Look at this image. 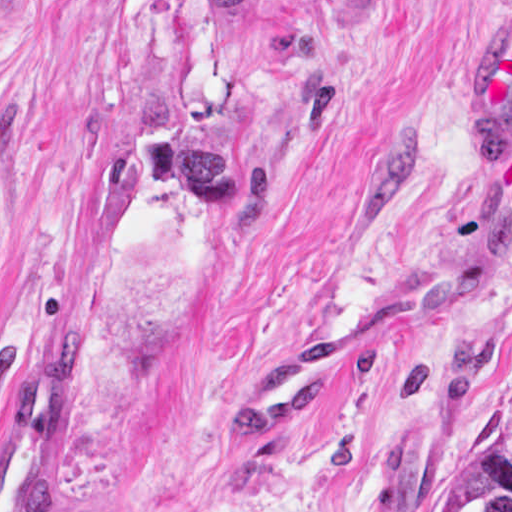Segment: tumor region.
<instances>
[{
	"label": "tumor region",
	"instance_id": "e687c5a6",
	"mask_svg": "<svg viewBox=\"0 0 512 512\" xmlns=\"http://www.w3.org/2000/svg\"><path fill=\"white\" fill-rule=\"evenodd\" d=\"M432 512H512V384L502 391L482 450L457 492Z\"/></svg>",
	"mask_w": 512,
	"mask_h": 512
}]
</instances>
